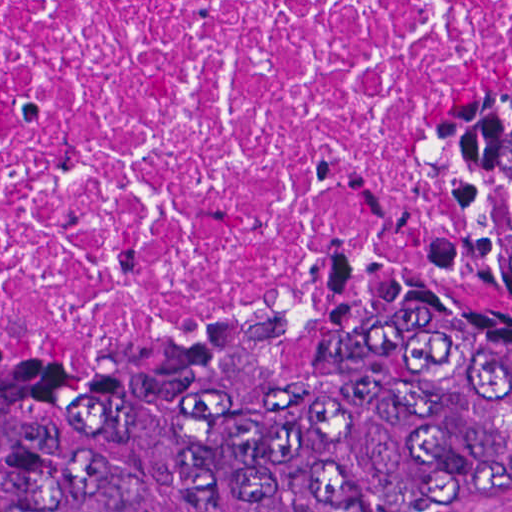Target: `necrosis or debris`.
<instances>
[{
	"mask_svg": "<svg viewBox=\"0 0 512 512\" xmlns=\"http://www.w3.org/2000/svg\"><path fill=\"white\" fill-rule=\"evenodd\" d=\"M511 58L512 0H0V355L188 343Z\"/></svg>",
	"mask_w": 512,
	"mask_h": 512,
	"instance_id": "4bbe7bcc",
	"label": "necrosis or debris"
}]
</instances>
